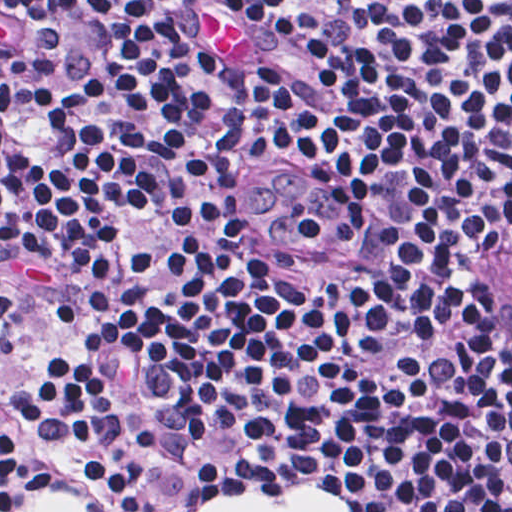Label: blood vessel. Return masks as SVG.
Instances as JSON below:
<instances>
[{
    "label": "blood vessel",
    "instance_id": "blood-vessel-1",
    "mask_svg": "<svg viewBox=\"0 0 512 512\" xmlns=\"http://www.w3.org/2000/svg\"><path fill=\"white\" fill-rule=\"evenodd\" d=\"M494 316L502 345L512 365V244L508 246L497 274Z\"/></svg>",
    "mask_w": 512,
    "mask_h": 512
}]
</instances>
